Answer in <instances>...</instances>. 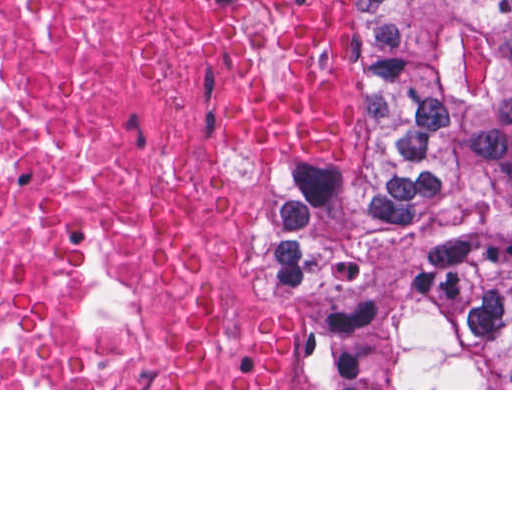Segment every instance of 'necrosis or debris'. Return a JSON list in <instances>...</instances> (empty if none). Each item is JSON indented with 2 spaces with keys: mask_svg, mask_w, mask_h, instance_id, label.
Here are the masks:
<instances>
[{
  "mask_svg": "<svg viewBox=\"0 0 512 512\" xmlns=\"http://www.w3.org/2000/svg\"><path fill=\"white\" fill-rule=\"evenodd\" d=\"M261 0H0V388H150L181 273L257 213L200 93Z\"/></svg>",
  "mask_w": 512,
  "mask_h": 512,
  "instance_id": "4bbe7bcc",
  "label": "necrosis or debris"
}]
</instances>
